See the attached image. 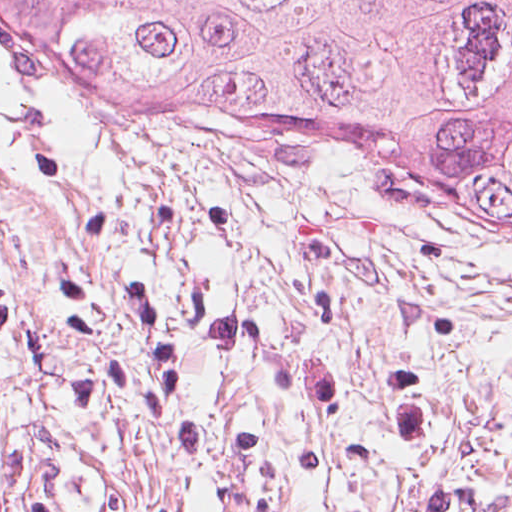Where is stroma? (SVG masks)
<instances>
[{
    "mask_svg": "<svg viewBox=\"0 0 512 512\" xmlns=\"http://www.w3.org/2000/svg\"><path fill=\"white\" fill-rule=\"evenodd\" d=\"M0 287L44 512H512V249L357 149L46 92L0 48Z\"/></svg>",
    "mask_w": 512,
    "mask_h": 512,
    "instance_id": "35a3bbf8",
    "label": "stroma"
}]
</instances>
